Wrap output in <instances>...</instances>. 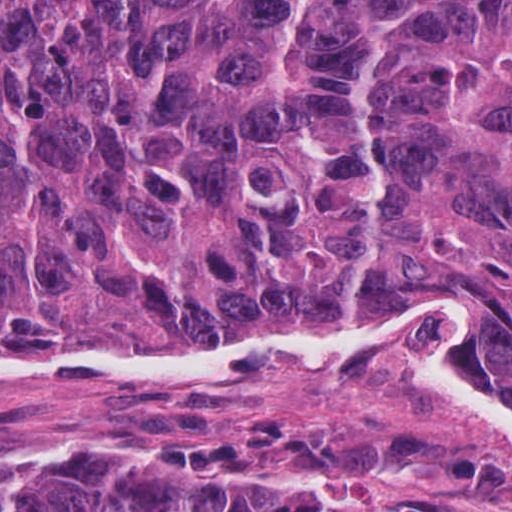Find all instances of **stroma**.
<instances>
[{"mask_svg":"<svg viewBox=\"0 0 512 512\" xmlns=\"http://www.w3.org/2000/svg\"><path fill=\"white\" fill-rule=\"evenodd\" d=\"M477 306L485 323L477 372L494 343L498 312L478 289L451 286L431 302L396 309L366 325L302 317L238 330L215 349L251 339H342L396 328L416 317ZM135 354L0 338V361H82ZM299 427L353 428L389 422L424 428L455 445L512 465L434 390L387 366H182L130 381H0V471L67 454L138 461L168 443L222 438L264 410ZM222 479L255 490L311 486L345 510L500 512L475 495L424 476H344L320 469H237Z\"/></svg>","mask_w":512,"mask_h":512,"instance_id":"35a3bbf8","label":"stroma"}]
</instances>
